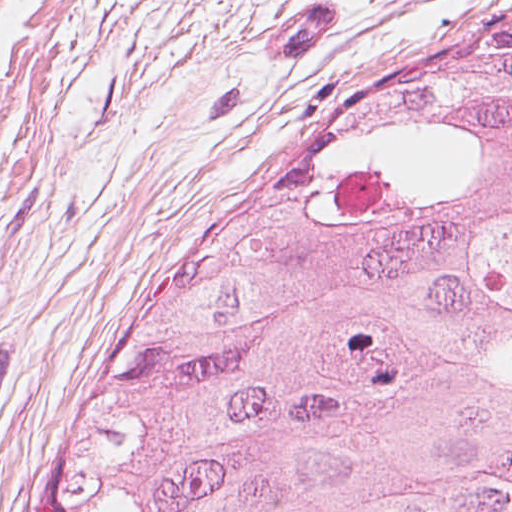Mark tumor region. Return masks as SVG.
Returning <instances> with one entry per match:
<instances>
[{"mask_svg":"<svg viewBox=\"0 0 512 512\" xmlns=\"http://www.w3.org/2000/svg\"><path fill=\"white\" fill-rule=\"evenodd\" d=\"M44 512H512V20L313 132Z\"/></svg>","mask_w":512,"mask_h":512,"instance_id":"tumor-region-1","label":"tumor region"}]
</instances>
